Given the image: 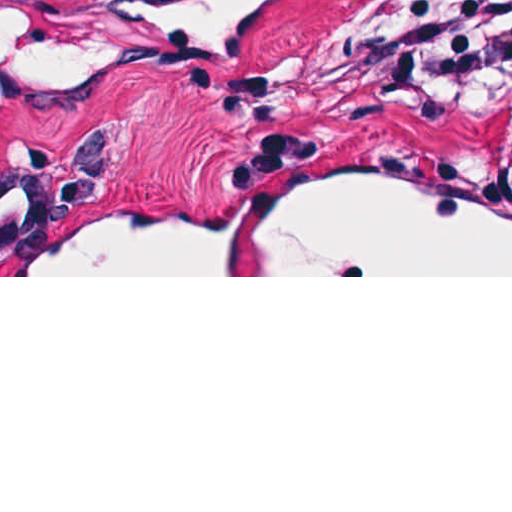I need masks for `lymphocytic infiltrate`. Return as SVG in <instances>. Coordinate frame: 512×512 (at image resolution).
Masks as SVG:
<instances>
[{"label": "lymphocytic infiltrate", "mask_w": 512, "mask_h": 512, "mask_svg": "<svg viewBox=\"0 0 512 512\" xmlns=\"http://www.w3.org/2000/svg\"><path fill=\"white\" fill-rule=\"evenodd\" d=\"M512 37V0H477L422 36V72L435 82L456 78L473 61ZM512 152V117L505 131Z\"/></svg>", "instance_id": "lymphocytic-infiltrate-1"}]
</instances>
